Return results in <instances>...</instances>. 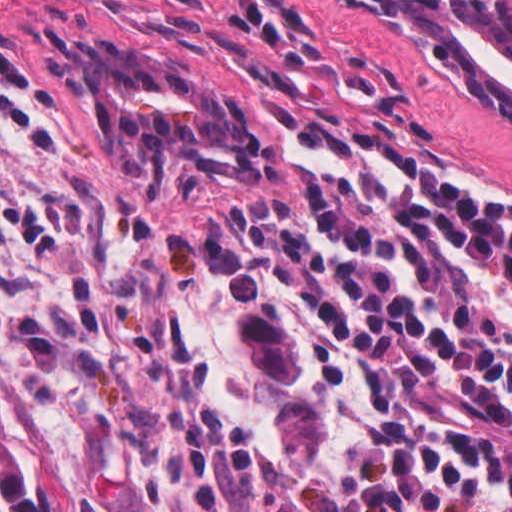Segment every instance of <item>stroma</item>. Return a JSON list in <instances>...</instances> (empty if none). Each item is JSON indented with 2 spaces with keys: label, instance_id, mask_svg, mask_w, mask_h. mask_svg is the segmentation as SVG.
I'll return each instance as SVG.
<instances>
[{
  "label": "stroma",
  "instance_id": "stroma-1",
  "mask_svg": "<svg viewBox=\"0 0 512 512\" xmlns=\"http://www.w3.org/2000/svg\"><path fill=\"white\" fill-rule=\"evenodd\" d=\"M512 5V0H505ZM27 77L0 90V394L33 484L26 419L90 512H126L142 333L118 299V229L268 158L328 170L491 162L512 187V129L430 91L338 0H0ZM107 40L258 117L243 153L114 167L64 91L69 43Z\"/></svg>",
  "mask_w": 512,
  "mask_h": 512
}]
</instances>
